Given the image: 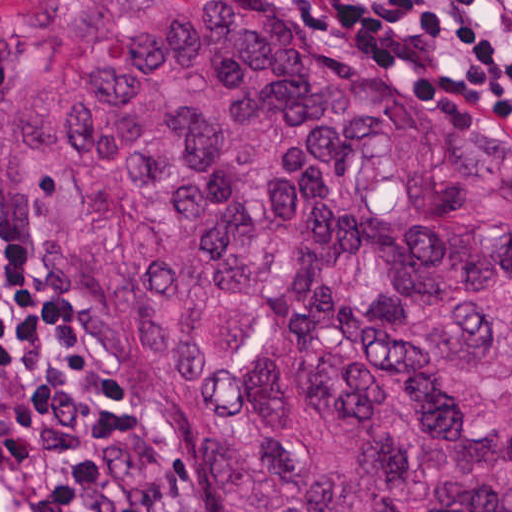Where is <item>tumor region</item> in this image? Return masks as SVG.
Listing matches in <instances>:
<instances>
[{"label": "tumor region", "instance_id": "tumor-region-1", "mask_svg": "<svg viewBox=\"0 0 512 512\" xmlns=\"http://www.w3.org/2000/svg\"><path fill=\"white\" fill-rule=\"evenodd\" d=\"M0 165L173 512H512V139L439 75L310 0H7Z\"/></svg>", "mask_w": 512, "mask_h": 512}]
</instances>
